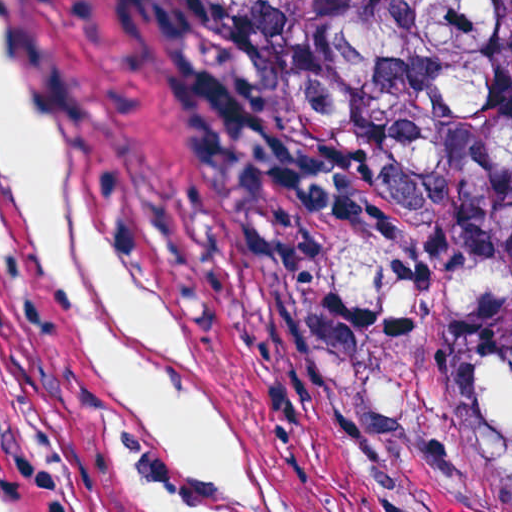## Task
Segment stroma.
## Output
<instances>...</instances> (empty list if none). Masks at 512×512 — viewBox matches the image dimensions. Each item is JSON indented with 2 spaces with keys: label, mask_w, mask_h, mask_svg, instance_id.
I'll list each match as a JSON object with an SVG mask.
<instances>
[{
  "label": "stroma",
  "mask_w": 512,
  "mask_h": 512,
  "mask_svg": "<svg viewBox=\"0 0 512 512\" xmlns=\"http://www.w3.org/2000/svg\"><path fill=\"white\" fill-rule=\"evenodd\" d=\"M7 1L111 249L205 356L282 512H372L158 1ZM0 426L47 512H160L151 425L23 210H0Z\"/></svg>",
  "instance_id": "35a3bbf8"
}]
</instances>
